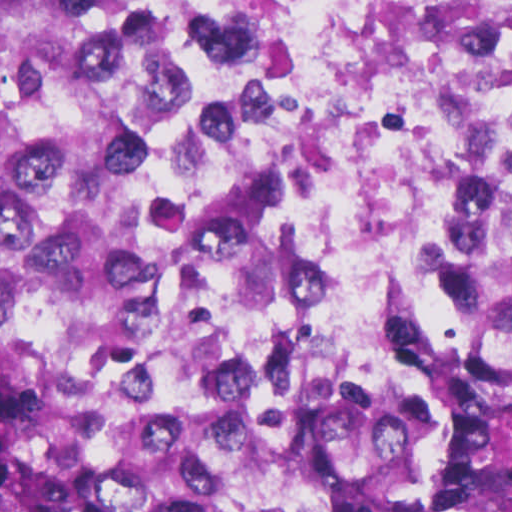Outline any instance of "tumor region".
<instances>
[{"label": "tumor region", "mask_w": 512, "mask_h": 512, "mask_svg": "<svg viewBox=\"0 0 512 512\" xmlns=\"http://www.w3.org/2000/svg\"><path fill=\"white\" fill-rule=\"evenodd\" d=\"M0 512H512V178L400 340L306 354L200 258L86 0H0Z\"/></svg>", "instance_id": "e687c5a6"}]
</instances>
